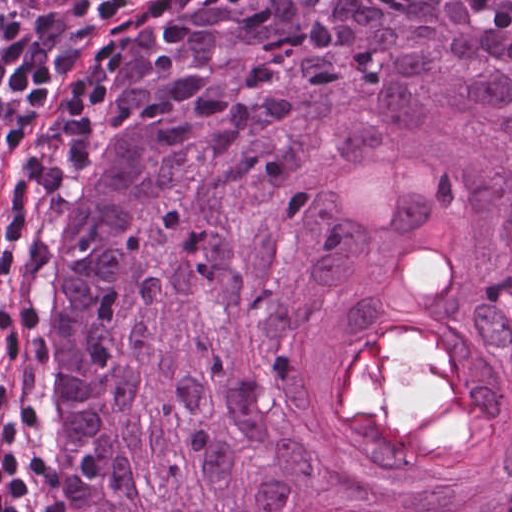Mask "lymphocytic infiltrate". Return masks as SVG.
I'll return each instance as SVG.
<instances>
[{
    "instance_id": "lymphocytic-infiltrate-1",
    "label": "lymphocytic infiltrate",
    "mask_w": 512,
    "mask_h": 512,
    "mask_svg": "<svg viewBox=\"0 0 512 512\" xmlns=\"http://www.w3.org/2000/svg\"><path fill=\"white\" fill-rule=\"evenodd\" d=\"M113 0L40 13L0 3V405L34 419L42 275L55 252L58 162L34 126L72 66L78 42ZM0 512H43L38 458L12 427L0 445Z\"/></svg>"
}]
</instances>
